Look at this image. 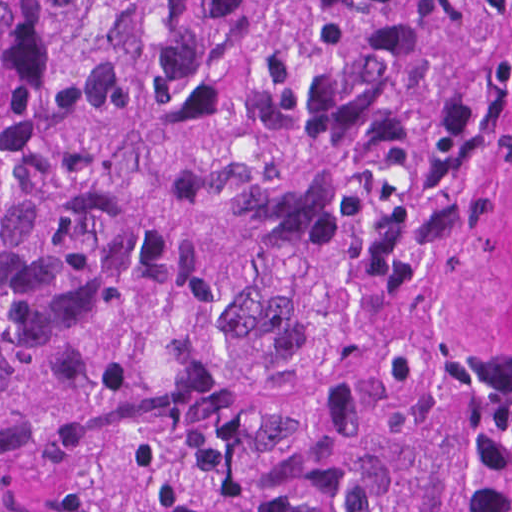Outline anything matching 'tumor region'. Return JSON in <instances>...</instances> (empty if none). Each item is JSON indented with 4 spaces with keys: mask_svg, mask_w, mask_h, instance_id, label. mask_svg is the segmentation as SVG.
Here are the masks:
<instances>
[{
    "mask_svg": "<svg viewBox=\"0 0 512 512\" xmlns=\"http://www.w3.org/2000/svg\"><path fill=\"white\" fill-rule=\"evenodd\" d=\"M0 512H512V0H0Z\"/></svg>",
    "mask_w": 512,
    "mask_h": 512,
    "instance_id": "tumor-region-1",
    "label": "tumor region"
}]
</instances>
